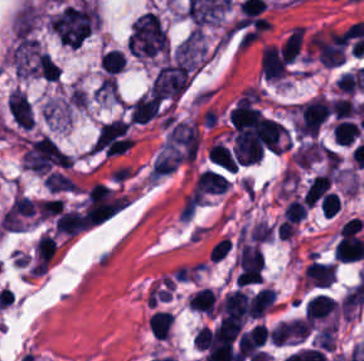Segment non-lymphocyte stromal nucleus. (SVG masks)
Instances as JSON below:
<instances>
[{
	"label": "non-lymphocyte stromal nucleus",
	"mask_w": 364,
	"mask_h": 361,
	"mask_svg": "<svg viewBox=\"0 0 364 361\" xmlns=\"http://www.w3.org/2000/svg\"><path fill=\"white\" fill-rule=\"evenodd\" d=\"M10 58L19 77H56L52 57L37 41L19 37Z\"/></svg>",
	"instance_id": "obj_1"
},
{
	"label": "non-lymphocyte stromal nucleus",
	"mask_w": 364,
	"mask_h": 361,
	"mask_svg": "<svg viewBox=\"0 0 364 361\" xmlns=\"http://www.w3.org/2000/svg\"><path fill=\"white\" fill-rule=\"evenodd\" d=\"M44 180L52 191H78V184L56 169L47 173Z\"/></svg>",
	"instance_id": "obj_2"
}]
</instances>
